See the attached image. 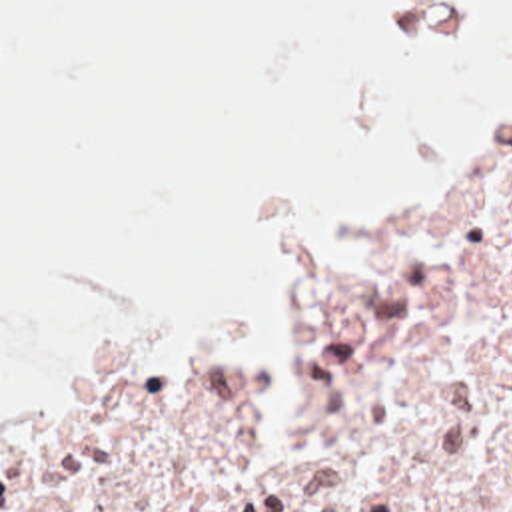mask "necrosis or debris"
<instances>
[{"label":"necrosis or debris","instance_id":"1","mask_svg":"<svg viewBox=\"0 0 512 512\" xmlns=\"http://www.w3.org/2000/svg\"><path fill=\"white\" fill-rule=\"evenodd\" d=\"M295 438L267 359L84 393L0 440V512H512V91L395 157L381 229L273 233Z\"/></svg>","mask_w":512,"mask_h":512}]
</instances>
